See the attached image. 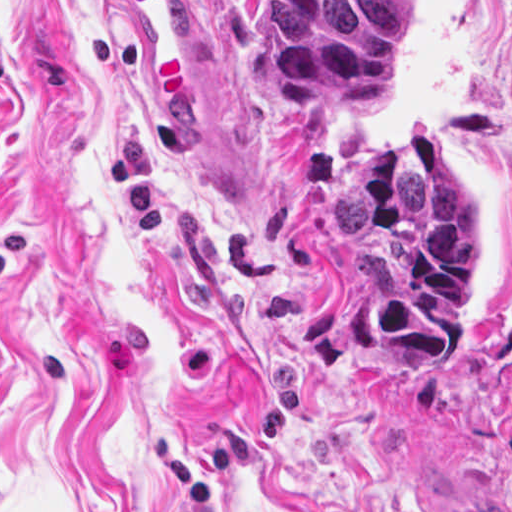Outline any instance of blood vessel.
<instances>
[{"label":"blood vessel","mask_w":512,"mask_h":512,"mask_svg":"<svg viewBox=\"0 0 512 512\" xmlns=\"http://www.w3.org/2000/svg\"><path fill=\"white\" fill-rule=\"evenodd\" d=\"M135 44V101L142 119L172 134L200 131L206 68L197 51L193 0H117Z\"/></svg>","instance_id":"obj_1"}]
</instances>
